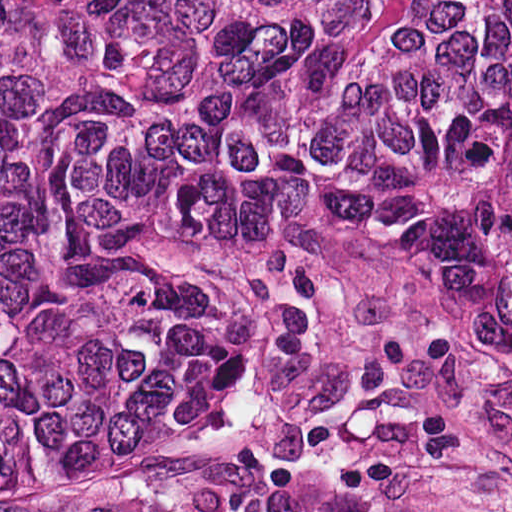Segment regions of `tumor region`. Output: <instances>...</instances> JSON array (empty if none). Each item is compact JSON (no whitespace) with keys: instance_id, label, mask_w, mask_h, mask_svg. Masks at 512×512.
Returning a JSON list of instances; mask_svg holds the SVG:
<instances>
[{"instance_id":"obj_1","label":"tumor region","mask_w":512,"mask_h":512,"mask_svg":"<svg viewBox=\"0 0 512 512\" xmlns=\"http://www.w3.org/2000/svg\"><path fill=\"white\" fill-rule=\"evenodd\" d=\"M242 213L408 243L512 354V0H0V492L170 407Z\"/></svg>"}]
</instances>
